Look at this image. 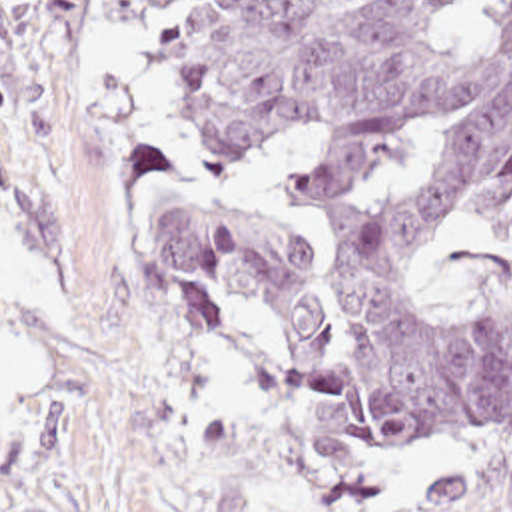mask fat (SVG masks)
Here are the masks:
<instances>
[{"label": "fat", "instance_id": "obj_1", "mask_svg": "<svg viewBox=\"0 0 512 512\" xmlns=\"http://www.w3.org/2000/svg\"><path fill=\"white\" fill-rule=\"evenodd\" d=\"M42 390L46 360L14 342H0V410H16Z\"/></svg>", "mask_w": 512, "mask_h": 512}]
</instances>
